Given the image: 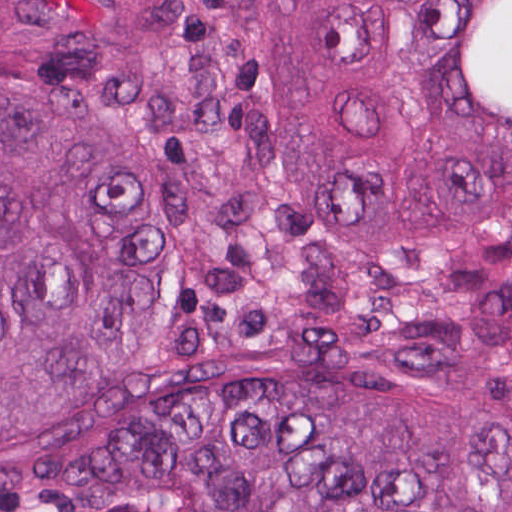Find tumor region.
I'll use <instances>...</instances> for the list:
<instances>
[{
    "instance_id": "e687c5a6",
    "label": "tumor region",
    "mask_w": 512,
    "mask_h": 512,
    "mask_svg": "<svg viewBox=\"0 0 512 512\" xmlns=\"http://www.w3.org/2000/svg\"><path fill=\"white\" fill-rule=\"evenodd\" d=\"M0 512H512V0H0Z\"/></svg>"
}]
</instances>
